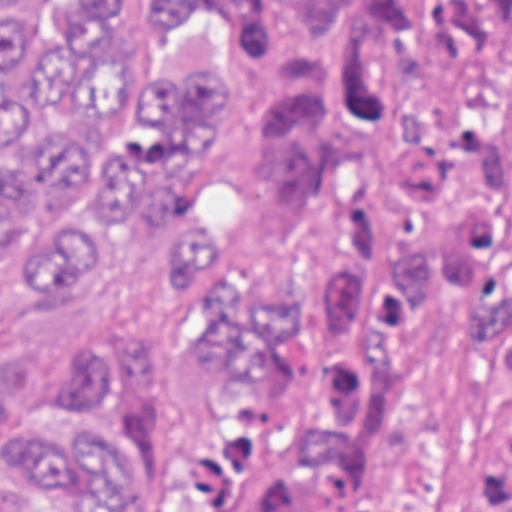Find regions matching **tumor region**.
Listing matches in <instances>:
<instances>
[{
  "label": "tumor region",
  "instance_id": "e687c5a6",
  "mask_svg": "<svg viewBox=\"0 0 512 512\" xmlns=\"http://www.w3.org/2000/svg\"><path fill=\"white\" fill-rule=\"evenodd\" d=\"M115 0H41L13 38L0 0V252L84 208L19 289L79 299L123 219L175 245V273L218 315L208 375L295 392L300 304L245 283L165 208L170 175L230 138V56H175L132 98ZM150 38L238 30L276 79L260 137L272 223L330 311L317 393L195 453L189 487L158 439L153 349L71 380L44 410L0 375L8 478L53 512H406L379 452L411 391L423 327L461 324L489 351L499 415L476 451V512H512V0H139ZM12 444V445H8Z\"/></svg>",
  "mask_w": 512,
  "mask_h": 512
}]
</instances>
